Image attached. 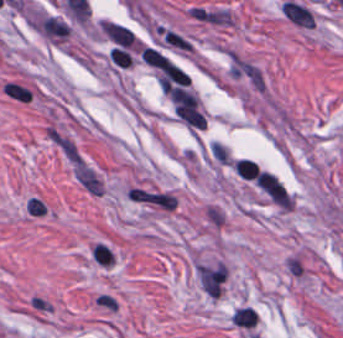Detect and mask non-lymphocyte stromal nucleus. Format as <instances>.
<instances>
[{"label":"non-lymphocyte stromal nucleus","mask_w":343,"mask_h":338,"mask_svg":"<svg viewBox=\"0 0 343 338\" xmlns=\"http://www.w3.org/2000/svg\"><path fill=\"white\" fill-rule=\"evenodd\" d=\"M200 284L209 297H218L225 282L226 266L219 263L200 265L196 269Z\"/></svg>","instance_id":"2"},{"label":"non-lymphocyte stromal nucleus","mask_w":343,"mask_h":338,"mask_svg":"<svg viewBox=\"0 0 343 338\" xmlns=\"http://www.w3.org/2000/svg\"><path fill=\"white\" fill-rule=\"evenodd\" d=\"M64 158L77 182L92 196H102L107 186L95 165L75 141H67Z\"/></svg>","instance_id":"1"},{"label":"non-lymphocyte stromal nucleus","mask_w":343,"mask_h":338,"mask_svg":"<svg viewBox=\"0 0 343 338\" xmlns=\"http://www.w3.org/2000/svg\"><path fill=\"white\" fill-rule=\"evenodd\" d=\"M233 324L237 328H253L258 320L257 312L251 306L235 308L231 316Z\"/></svg>","instance_id":"5"},{"label":"non-lymphocyte stromal nucleus","mask_w":343,"mask_h":338,"mask_svg":"<svg viewBox=\"0 0 343 338\" xmlns=\"http://www.w3.org/2000/svg\"><path fill=\"white\" fill-rule=\"evenodd\" d=\"M100 28L108 39L120 47H131L133 43V34L129 28L108 21H101Z\"/></svg>","instance_id":"3"},{"label":"non-lymphocyte stromal nucleus","mask_w":343,"mask_h":338,"mask_svg":"<svg viewBox=\"0 0 343 338\" xmlns=\"http://www.w3.org/2000/svg\"><path fill=\"white\" fill-rule=\"evenodd\" d=\"M283 268L289 278L304 279L305 277V259L298 252L293 251L284 257Z\"/></svg>","instance_id":"4"},{"label":"non-lymphocyte stromal nucleus","mask_w":343,"mask_h":338,"mask_svg":"<svg viewBox=\"0 0 343 338\" xmlns=\"http://www.w3.org/2000/svg\"><path fill=\"white\" fill-rule=\"evenodd\" d=\"M92 303L96 308L111 314L119 307L116 297L106 291H98Z\"/></svg>","instance_id":"6"}]
</instances>
